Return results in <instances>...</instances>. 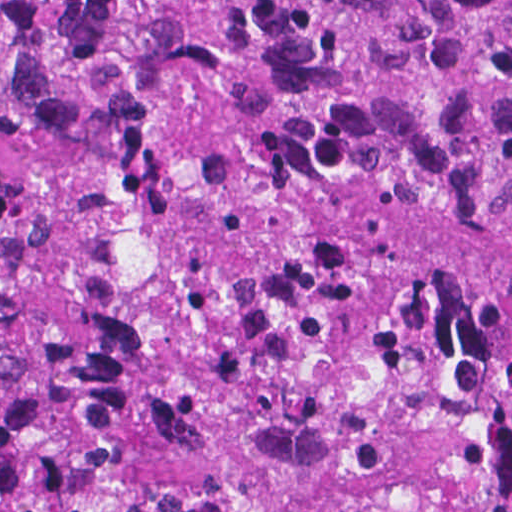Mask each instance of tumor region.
Here are the masks:
<instances>
[{"instance_id": "tumor-region-1", "label": "tumor region", "mask_w": 512, "mask_h": 512, "mask_svg": "<svg viewBox=\"0 0 512 512\" xmlns=\"http://www.w3.org/2000/svg\"><path fill=\"white\" fill-rule=\"evenodd\" d=\"M0 512H512V0H0Z\"/></svg>"}]
</instances>
